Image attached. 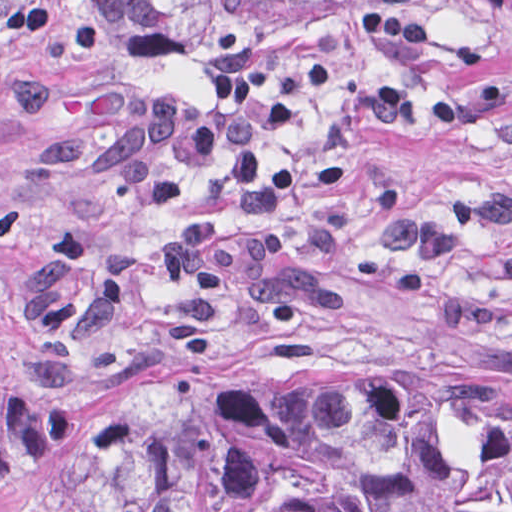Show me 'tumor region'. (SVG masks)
Here are the masks:
<instances>
[{"label":"tumor region","mask_w":512,"mask_h":512,"mask_svg":"<svg viewBox=\"0 0 512 512\" xmlns=\"http://www.w3.org/2000/svg\"><path fill=\"white\" fill-rule=\"evenodd\" d=\"M150 59L427 31L512 0H97ZM274 386L296 391H214ZM512 384L191 372L69 433L60 512H512Z\"/></svg>","instance_id":"e687c5a6"}]
</instances>
